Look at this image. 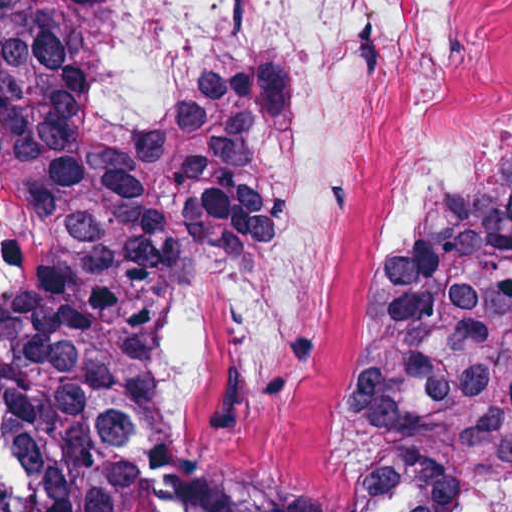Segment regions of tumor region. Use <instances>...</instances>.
I'll use <instances>...</instances> for the list:
<instances>
[{
	"label": "tumor region",
	"instance_id": "obj_1",
	"mask_svg": "<svg viewBox=\"0 0 512 512\" xmlns=\"http://www.w3.org/2000/svg\"><path fill=\"white\" fill-rule=\"evenodd\" d=\"M82 0H0V512H123L92 408L280 209L309 73L265 61L145 121L74 125ZM331 512H512V151L429 216L349 352Z\"/></svg>",
	"mask_w": 512,
	"mask_h": 512
}]
</instances>
